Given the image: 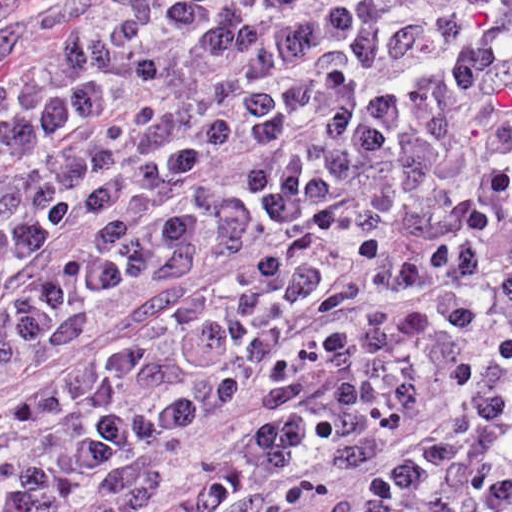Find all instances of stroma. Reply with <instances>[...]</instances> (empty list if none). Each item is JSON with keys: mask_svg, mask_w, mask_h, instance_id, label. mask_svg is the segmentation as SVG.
Instances as JSON below:
<instances>
[{"mask_svg": "<svg viewBox=\"0 0 512 512\" xmlns=\"http://www.w3.org/2000/svg\"><path fill=\"white\" fill-rule=\"evenodd\" d=\"M62 0H0V40L37 13ZM150 296V277L120 281L106 309L66 349L46 352L0 369V421L92 347L129 332ZM381 464L341 469H296L263 490L247 493L220 512H319L345 485Z\"/></svg>", "mask_w": 512, "mask_h": 512, "instance_id": "1", "label": "stroma"}]
</instances>
